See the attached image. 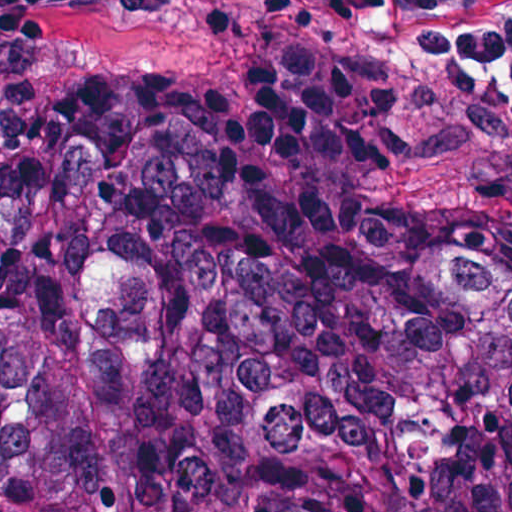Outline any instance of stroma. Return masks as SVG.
Segmentation results:
<instances>
[{
    "instance_id": "1",
    "label": "stroma",
    "mask_w": 512,
    "mask_h": 512,
    "mask_svg": "<svg viewBox=\"0 0 512 512\" xmlns=\"http://www.w3.org/2000/svg\"><path fill=\"white\" fill-rule=\"evenodd\" d=\"M275 125L512 249V0H0V177Z\"/></svg>"
}]
</instances>
